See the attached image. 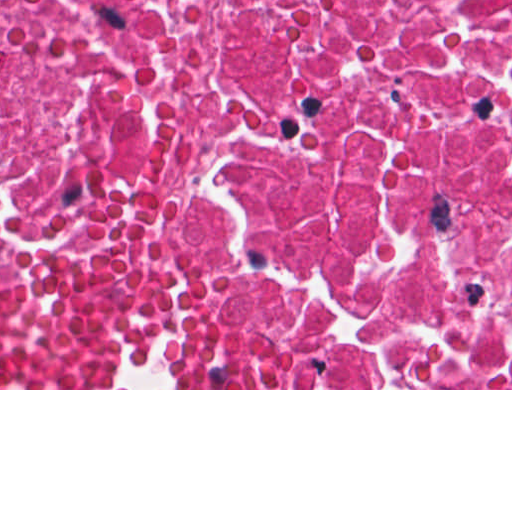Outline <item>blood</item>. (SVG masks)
<instances>
[{
	"mask_svg": "<svg viewBox=\"0 0 512 512\" xmlns=\"http://www.w3.org/2000/svg\"><path fill=\"white\" fill-rule=\"evenodd\" d=\"M0 388H236L140 258L89 253L51 301L0 306Z\"/></svg>",
	"mask_w": 512,
	"mask_h": 512,
	"instance_id": "1",
	"label": "blood"
}]
</instances>
